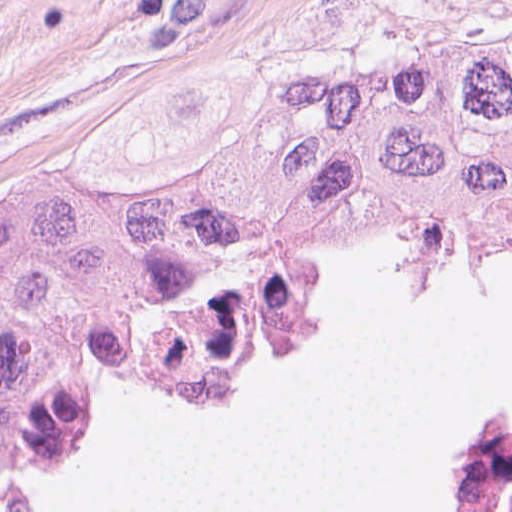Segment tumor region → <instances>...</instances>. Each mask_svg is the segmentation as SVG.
Wrapping results in <instances>:
<instances>
[{
    "label": "tumor region",
    "mask_w": 512,
    "mask_h": 512,
    "mask_svg": "<svg viewBox=\"0 0 512 512\" xmlns=\"http://www.w3.org/2000/svg\"><path fill=\"white\" fill-rule=\"evenodd\" d=\"M403 234L415 294L512 267V32L284 86L152 193L0 180V512L79 453L98 391L211 402L317 332L323 243Z\"/></svg>",
    "instance_id": "tumor-region-1"
}]
</instances>
